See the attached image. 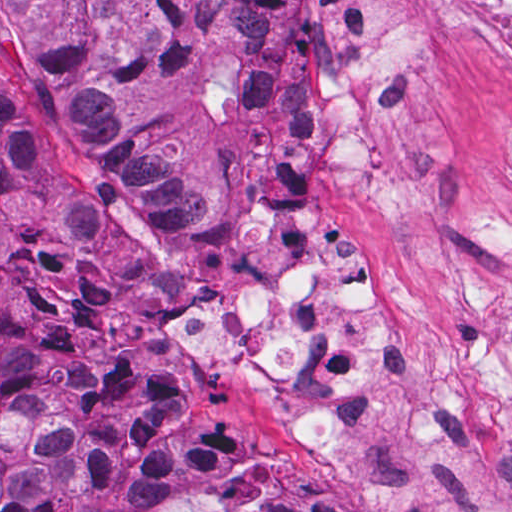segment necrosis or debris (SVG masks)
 <instances>
[{
	"mask_svg": "<svg viewBox=\"0 0 512 512\" xmlns=\"http://www.w3.org/2000/svg\"><path fill=\"white\" fill-rule=\"evenodd\" d=\"M472 37L512 61V0H320L309 37L305 125L340 200L426 186L446 167L411 119L422 62ZM383 260L345 248L313 257L265 235L213 301L182 309L181 340L229 372L260 374L303 454L364 457L376 427L405 419L424 441L482 453L512 408V350L426 351L407 370L380 321Z\"/></svg>",
	"mask_w": 512,
	"mask_h": 512,
	"instance_id": "1",
	"label": "necrosis or debris"
}]
</instances>
